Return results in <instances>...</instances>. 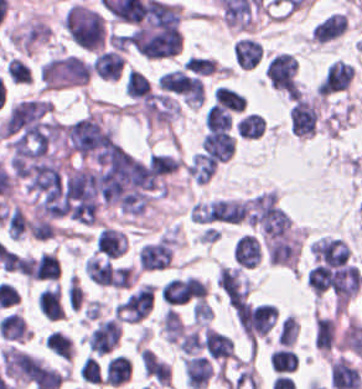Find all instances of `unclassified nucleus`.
Listing matches in <instances>:
<instances>
[{
    "label": "unclassified nucleus",
    "instance_id": "obj_1",
    "mask_svg": "<svg viewBox=\"0 0 362 389\" xmlns=\"http://www.w3.org/2000/svg\"><path fill=\"white\" fill-rule=\"evenodd\" d=\"M93 179L102 200L127 214H139L165 191L156 171L118 144L100 153Z\"/></svg>",
    "mask_w": 362,
    "mask_h": 389
},
{
    "label": "unclassified nucleus",
    "instance_id": "obj_2",
    "mask_svg": "<svg viewBox=\"0 0 362 389\" xmlns=\"http://www.w3.org/2000/svg\"><path fill=\"white\" fill-rule=\"evenodd\" d=\"M112 133L104 121L96 115L85 116L61 128L66 153L83 158L98 150Z\"/></svg>",
    "mask_w": 362,
    "mask_h": 389
}]
</instances>
